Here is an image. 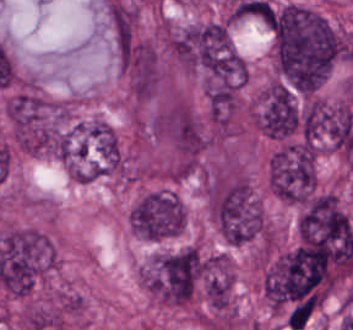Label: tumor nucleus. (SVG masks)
<instances>
[{"label": "tumor nucleus", "mask_w": 353, "mask_h": 330, "mask_svg": "<svg viewBox=\"0 0 353 330\" xmlns=\"http://www.w3.org/2000/svg\"><path fill=\"white\" fill-rule=\"evenodd\" d=\"M5 115L12 139L25 152L66 154L71 125L68 102L23 88L6 99Z\"/></svg>", "instance_id": "obj_1"}, {"label": "tumor nucleus", "mask_w": 353, "mask_h": 330, "mask_svg": "<svg viewBox=\"0 0 353 330\" xmlns=\"http://www.w3.org/2000/svg\"><path fill=\"white\" fill-rule=\"evenodd\" d=\"M204 274V257L191 244L156 252L139 268L148 293L167 304L193 299Z\"/></svg>", "instance_id": "obj_2"}, {"label": "tumor nucleus", "mask_w": 353, "mask_h": 330, "mask_svg": "<svg viewBox=\"0 0 353 330\" xmlns=\"http://www.w3.org/2000/svg\"><path fill=\"white\" fill-rule=\"evenodd\" d=\"M316 182V147L310 142L279 139L267 160L269 191L289 204H303Z\"/></svg>", "instance_id": "obj_3"}, {"label": "tumor nucleus", "mask_w": 353, "mask_h": 330, "mask_svg": "<svg viewBox=\"0 0 353 330\" xmlns=\"http://www.w3.org/2000/svg\"><path fill=\"white\" fill-rule=\"evenodd\" d=\"M302 248L353 250V223L338 195L317 191L301 206L297 221Z\"/></svg>", "instance_id": "obj_4"}, {"label": "tumor nucleus", "mask_w": 353, "mask_h": 330, "mask_svg": "<svg viewBox=\"0 0 353 330\" xmlns=\"http://www.w3.org/2000/svg\"><path fill=\"white\" fill-rule=\"evenodd\" d=\"M186 209L172 189H153L141 197L128 212L129 229L139 238L161 240L182 231Z\"/></svg>", "instance_id": "obj_5"}, {"label": "tumor nucleus", "mask_w": 353, "mask_h": 330, "mask_svg": "<svg viewBox=\"0 0 353 330\" xmlns=\"http://www.w3.org/2000/svg\"><path fill=\"white\" fill-rule=\"evenodd\" d=\"M252 124L264 135L286 137L300 122L297 98L281 79H268L252 96Z\"/></svg>", "instance_id": "obj_6"}, {"label": "tumor nucleus", "mask_w": 353, "mask_h": 330, "mask_svg": "<svg viewBox=\"0 0 353 330\" xmlns=\"http://www.w3.org/2000/svg\"><path fill=\"white\" fill-rule=\"evenodd\" d=\"M19 321L29 330H60L63 328L62 309L30 305L23 309Z\"/></svg>", "instance_id": "obj_7"}]
</instances>
